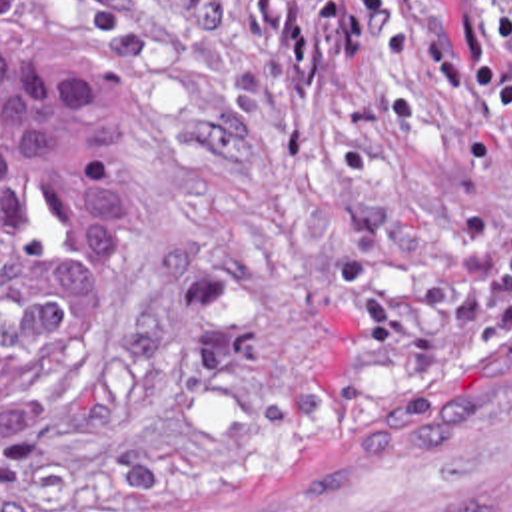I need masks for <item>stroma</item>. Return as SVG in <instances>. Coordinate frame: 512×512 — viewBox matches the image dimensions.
<instances>
[{"instance_id": "35a3bbf8", "label": "stroma", "mask_w": 512, "mask_h": 512, "mask_svg": "<svg viewBox=\"0 0 512 512\" xmlns=\"http://www.w3.org/2000/svg\"><path fill=\"white\" fill-rule=\"evenodd\" d=\"M70 2L132 110L134 260L0 424V512L208 501L314 398L512 350V126L338 0Z\"/></svg>"}]
</instances>
